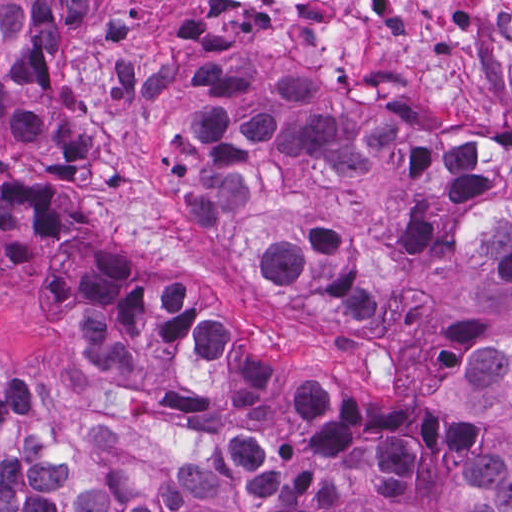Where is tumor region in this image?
Returning a JSON list of instances; mask_svg holds the SVG:
<instances>
[{
    "label": "tumor region",
    "instance_id": "obj_1",
    "mask_svg": "<svg viewBox=\"0 0 512 512\" xmlns=\"http://www.w3.org/2000/svg\"><path fill=\"white\" fill-rule=\"evenodd\" d=\"M92 0H0V242L77 197L85 142L70 50ZM160 147L192 219L279 290L389 318L418 290L512 297V168L424 178L397 147L308 137L261 67L180 75ZM39 339L75 370L221 421L218 456L168 461L79 434L0 382V512H512V350L472 361L455 399L474 454L405 457L368 478L312 456L478 440L419 407L369 412L349 375L282 384L196 300L124 282L96 252L42 293Z\"/></svg>",
    "mask_w": 512,
    "mask_h": 512
}]
</instances>
